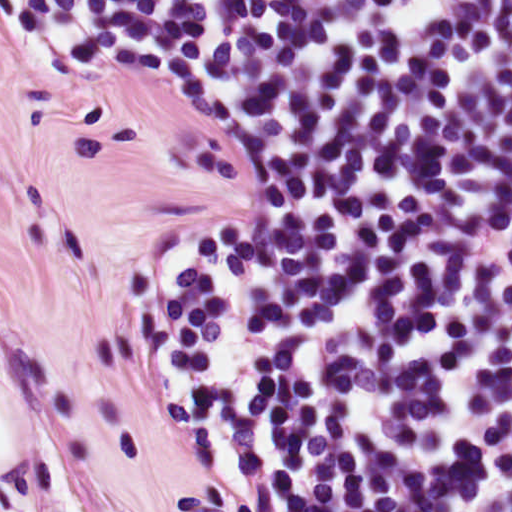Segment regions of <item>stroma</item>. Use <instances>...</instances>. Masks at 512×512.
I'll return each mask as SVG.
<instances>
[{
    "instance_id": "1",
    "label": "stroma",
    "mask_w": 512,
    "mask_h": 512,
    "mask_svg": "<svg viewBox=\"0 0 512 512\" xmlns=\"http://www.w3.org/2000/svg\"><path fill=\"white\" fill-rule=\"evenodd\" d=\"M248 190L225 109L0 38V512H226L158 402L139 301Z\"/></svg>"
}]
</instances>
